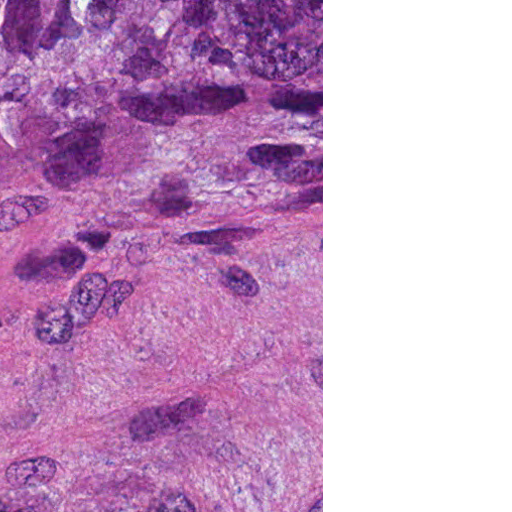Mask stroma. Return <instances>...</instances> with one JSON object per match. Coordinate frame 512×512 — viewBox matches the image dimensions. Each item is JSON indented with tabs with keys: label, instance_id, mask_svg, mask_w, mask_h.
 <instances>
[{
	"label": "stroma",
	"instance_id": "35a3bbf8",
	"mask_svg": "<svg viewBox=\"0 0 512 512\" xmlns=\"http://www.w3.org/2000/svg\"><path fill=\"white\" fill-rule=\"evenodd\" d=\"M36 1L0 219V512H323V0Z\"/></svg>",
	"mask_w": 512,
	"mask_h": 512
}]
</instances>
